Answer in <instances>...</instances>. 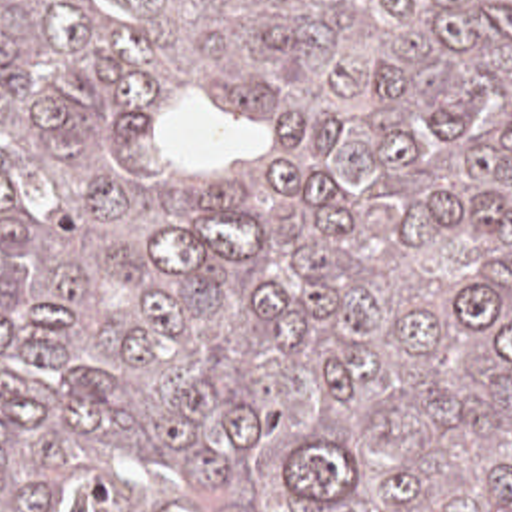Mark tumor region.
Instances as JSON below:
<instances>
[{
	"instance_id": "1",
	"label": "tumor region",
	"mask_w": 512,
	"mask_h": 512,
	"mask_svg": "<svg viewBox=\"0 0 512 512\" xmlns=\"http://www.w3.org/2000/svg\"><path fill=\"white\" fill-rule=\"evenodd\" d=\"M0 512H512V0H0Z\"/></svg>"
}]
</instances>
